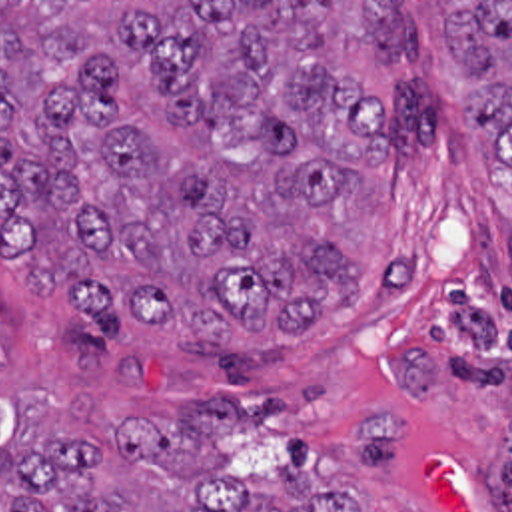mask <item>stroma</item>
Returning a JSON list of instances; mask_svg holds the SVG:
<instances>
[{
  "label": "stroma",
  "mask_w": 512,
  "mask_h": 512,
  "mask_svg": "<svg viewBox=\"0 0 512 512\" xmlns=\"http://www.w3.org/2000/svg\"><path fill=\"white\" fill-rule=\"evenodd\" d=\"M418 2L414 60L335 48L376 88L394 134L329 208L327 236L370 279L321 329L251 335L103 327L33 297L0 252V437L149 429L209 415L223 453L287 461L363 512H512V168L446 46L440 2L512 0H0ZM5 487L0 483V511Z\"/></svg>",
  "instance_id": "35a3bbf8"
}]
</instances>
